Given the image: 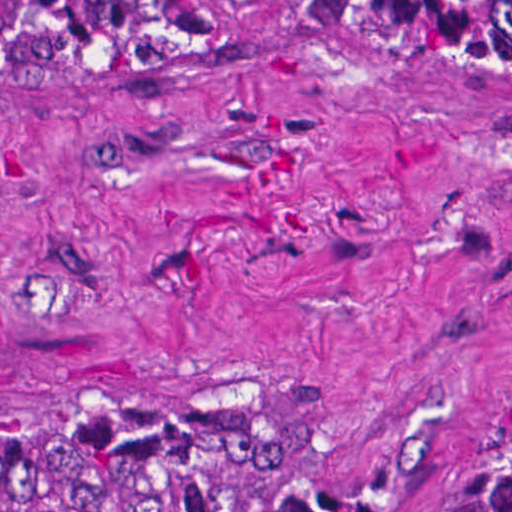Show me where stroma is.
Listing matches in <instances>:
<instances>
[{"label": "stroma", "mask_w": 512, "mask_h": 512, "mask_svg": "<svg viewBox=\"0 0 512 512\" xmlns=\"http://www.w3.org/2000/svg\"><path fill=\"white\" fill-rule=\"evenodd\" d=\"M127 377L282 391L254 512H398L512 413V76L184 8L137 62L0 0L1 421Z\"/></svg>", "instance_id": "1"}]
</instances>
